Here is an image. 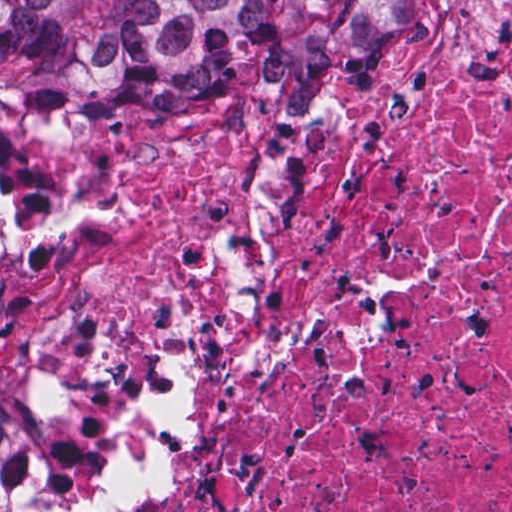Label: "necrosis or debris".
<instances>
[{
  "mask_svg": "<svg viewBox=\"0 0 512 512\" xmlns=\"http://www.w3.org/2000/svg\"><path fill=\"white\" fill-rule=\"evenodd\" d=\"M335 91L34 135L0 375L65 512H512V1Z\"/></svg>",
  "mask_w": 512,
  "mask_h": 512,
  "instance_id": "obj_1",
  "label": "necrosis or debris"
}]
</instances>
